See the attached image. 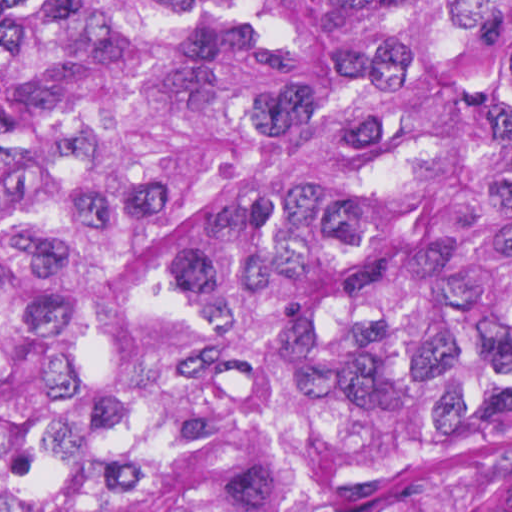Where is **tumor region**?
Masks as SVG:
<instances>
[{
  "instance_id": "e687c5a6",
  "label": "tumor region",
  "mask_w": 512,
  "mask_h": 512,
  "mask_svg": "<svg viewBox=\"0 0 512 512\" xmlns=\"http://www.w3.org/2000/svg\"><path fill=\"white\" fill-rule=\"evenodd\" d=\"M0 512H512V0H0Z\"/></svg>"
}]
</instances>
